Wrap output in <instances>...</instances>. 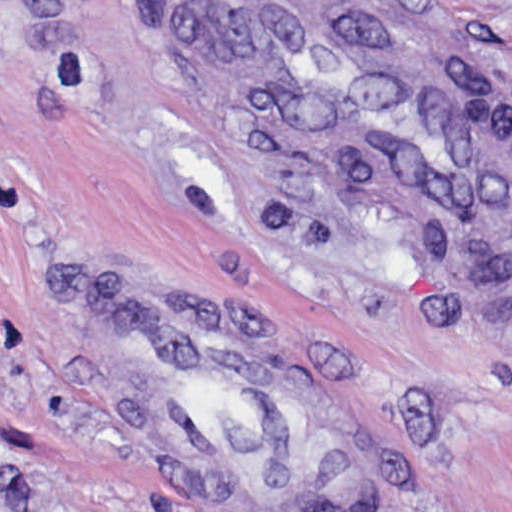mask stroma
Listing matches in <instances>:
<instances>
[{"label":"stroma","instance_id":"obj_1","mask_svg":"<svg viewBox=\"0 0 512 512\" xmlns=\"http://www.w3.org/2000/svg\"><path fill=\"white\" fill-rule=\"evenodd\" d=\"M433 2L512 91V0ZM83 276L252 326L338 422L347 512H512V223L273 158L155 0H0V512H201L80 362Z\"/></svg>","mask_w":512,"mask_h":512}]
</instances>
